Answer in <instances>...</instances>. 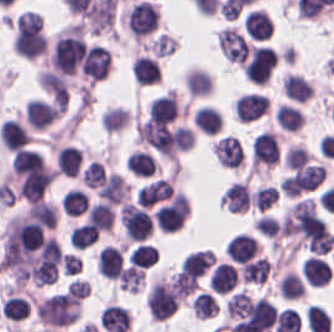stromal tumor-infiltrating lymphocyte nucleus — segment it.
<instances>
[{"instance_id":"stromal-tumor-infiltrating-lymphocyte-nucleus-1","label":"stromal tumor-infiltrating lymphocyte nucleus","mask_w":334,"mask_h":332,"mask_svg":"<svg viewBox=\"0 0 334 332\" xmlns=\"http://www.w3.org/2000/svg\"><path fill=\"white\" fill-rule=\"evenodd\" d=\"M158 21L157 6L146 0L136 1L125 17L129 32L135 36H144L155 28Z\"/></svg>"},{"instance_id":"stromal-tumor-infiltrating-lymphocyte-nucleus-2","label":"stromal tumor-infiltrating lymphocyte nucleus","mask_w":334,"mask_h":332,"mask_svg":"<svg viewBox=\"0 0 334 332\" xmlns=\"http://www.w3.org/2000/svg\"><path fill=\"white\" fill-rule=\"evenodd\" d=\"M148 307L152 316L161 321L177 310V295L166 280L156 279L152 284Z\"/></svg>"},{"instance_id":"stromal-tumor-infiltrating-lymphocyte-nucleus-3","label":"stromal tumor-infiltrating lymphocyte nucleus","mask_w":334,"mask_h":332,"mask_svg":"<svg viewBox=\"0 0 334 332\" xmlns=\"http://www.w3.org/2000/svg\"><path fill=\"white\" fill-rule=\"evenodd\" d=\"M110 51L101 44H88L81 55L82 75L93 80L103 79L109 72Z\"/></svg>"},{"instance_id":"stromal-tumor-infiltrating-lymphocyte-nucleus-4","label":"stromal tumor-infiltrating lymphocyte nucleus","mask_w":334,"mask_h":332,"mask_svg":"<svg viewBox=\"0 0 334 332\" xmlns=\"http://www.w3.org/2000/svg\"><path fill=\"white\" fill-rule=\"evenodd\" d=\"M219 50L227 60L245 63L249 53V42L232 26L221 28L217 36Z\"/></svg>"},{"instance_id":"stromal-tumor-infiltrating-lymphocyte-nucleus-5","label":"stromal tumor-infiltrating lymphocyte nucleus","mask_w":334,"mask_h":332,"mask_svg":"<svg viewBox=\"0 0 334 332\" xmlns=\"http://www.w3.org/2000/svg\"><path fill=\"white\" fill-rule=\"evenodd\" d=\"M212 148L223 167H239L243 163L242 143L237 136L224 134L213 142Z\"/></svg>"},{"instance_id":"stromal-tumor-infiltrating-lymphocyte-nucleus-6","label":"stromal tumor-infiltrating lymphocyte nucleus","mask_w":334,"mask_h":332,"mask_svg":"<svg viewBox=\"0 0 334 332\" xmlns=\"http://www.w3.org/2000/svg\"><path fill=\"white\" fill-rule=\"evenodd\" d=\"M57 111L51 103L31 97L25 103L24 117L31 127L42 130L53 121Z\"/></svg>"},{"instance_id":"stromal-tumor-infiltrating-lymphocyte-nucleus-7","label":"stromal tumor-infiltrating lymphocyte nucleus","mask_w":334,"mask_h":332,"mask_svg":"<svg viewBox=\"0 0 334 332\" xmlns=\"http://www.w3.org/2000/svg\"><path fill=\"white\" fill-rule=\"evenodd\" d=\"M268 105L264 95L255 92L241 94L234 102V116L236 119L254 120L266 111Z\"/></svg>"},{"instance_id":"stromal-tumor-infiltrating-lymphocyte-nucleus-8","label":"stromal tumor-infiltrating lymphocyte nucleus","mask_w":334,"mask_h":332,"mask_svg":"<svg viewBox=\"0 0 334 332\" xmlns=\"http://www.w3.org/2000/svg\"><path fill=\"white\" fill-rule=\"evenodd\" d=\"M123 265V250L119 245L104 244L96 255L99 274L117 278Z\"/></svg>"},{"instance_id":"stromal-tumor-infiltrating-lymphocyte-nucleus-9","label":"stromal tumor-infiltrating lymphocyte nucleus","mask_w":334,"mask_h":332,"mask_svg":"<svg viewBox=\"0 0 334 332\" xmlns=\"http://www.w3.org/2000/svg\"><path fill=\"white\" fill-rule=\"evenodd\" d=\"M237 278L238 273L230 261H217L210 272L208 286L213 292L227 293Z\"/></svg>"},{"instance_id":"stromal-tumor-infiltrating-lymphocyte-nucleus-10","label":"stromal tumor-infiltrating lymphocyte nucleus","mask_w":334,"mask_h":332,"mask_svg":"<svg viewBox=\"0 0 334 332\" xmlns=\"http://www.w3.org/2000/svg\"><path fill=\"white\" fill-rule=\"evenodd\" d=\"M250 203L248 183L234 180L222 193L221 204L236 212H244Z\"/></svg>"},{"instance_id":"stromal-tumor-infiltrating-lymphocyte-nucleus-11","label":"stromal tumor-infiltrating lymphocyte nucleus","mask_w":334,"mask_h":332,"mask_svg":"<svg viewBox=\"0 0 334 332\" xmlns=\"http://www.w3.org/2000/svg\"><path fill=\"white\" fill-rule=\"evenodd\" d=\"M31 137L27 129L13 118H6L0 124L1 143L9 150L15 151L26 145Z\"/></svg>"},{"instance_id":"stromal-tumor-infiltrating-lymphocyte-nucleus-12","label":"stromal tumor-infiltrating lymphocyte nucleus","mask_w":334,"mask_h":332,"mask_svg":"<svg viewBox=\"0 0 334 332\" xmlns=\"http://www.w3.org/2000/svg\"><path fill=\"white\" fill-rule=\"evenodd\" d=\"M259 247L254 235L245 233L234 234L226 245V253L238 261L250 260L258 253Z\"/></svg>"},{"instance_id":"stromal-tumor-infiltrating-lymphocyte-nucleus-13","label":"stromal tumor-infiltrating lymphocyte nucleus","mask_w":334,"mask_h":332,"mask_svg":"<svg viewBox=\"0 0 334 332\" xmlns=\"http://www.w3.org/2000/svg\"><path fill=\"white\" fill-rule=\"evenodd\" d=\"M272 30L273 23L265 10L253 9L244 17V32L252 39L263 41Z\"/></svg>"},{"instance_id":"stromal-tumor-infiltrating-lymphocyte-nucleus-14","label":"stromal tumor-infiltrating lymphocyte nucleus","mask_w":334,"mask_h":332,"mask_svg":"<svg viewBox=\"0 0 334 332\" xmlns=\"http://www.w3.org/2000/svg\"><path fill=\"white\" fill-rule=\"evenodd\" d=\"M305 280L315 285H323L332 276V266L325 259L309 255L300 266Z\"/></svg>"},{"instance_id":"stromal-tumor-infiltrating-lymphocyte-nucleus-15","label":"stromal tumor-infiltrating lymphocyte nucleus","mask_w":334,"mask_h":332,"mask_svg":"<svg viewBox=\"0 0 334 332\" xmlns=\"http://www.w3.org/2000/svg\"><path fill=\"white\" fill-rule=\"evenodd\" d=\"M83 150L74 145L60 147L55 154V169L62 174L74 176L80 170Z\"/></svg>"},{"instance_id":"stromal-tumor-infiltrating-lymphocyte-nucleus-16","label":"stromal tumor-infiltrating lymphocyte nucleus","mask_w":334,"mask_h":332,"mask_svg":"<svg viewBox=\"0 0 334 332\" xmlns=\"http://www.w3.org/2000/svg\"><path fill=\"white\" fill-rule=\"evenodd\" d=\"M86 219L94 229L109 231L114 220L113 206L99 199L87 209Z\"/></svg>"},{"instance_id":"stromal-tumor-infiltrating-lymphocyte-nucleus-17","label":"stromal tumor-infiltrating lymphocyte nucleus","mask_w":334,"mask_h":332,"mask_svg":"<svg viewBox=\"0 0 334 332\" xmlns=\"http://www.w3.org/2000/svg\"><path fill=\"white\" fill-rule=\"evenodd\" d=\"M133 75L141 84L154 82L160 76V66L155 57L136 54L131 66Z\"/></svg>"},{"instance_id":"stromal-tumor-infiltrating-lymphocyte-nucleus-18","label":"stromal tumor-infiltrating lymphocyte nucleus","mask_w":334,"mask_h":332,"mask_svg":"<svg viewBox=\"0 0 334 332\" xmlns=\"http://www.w3.org/2000/svg\"><path fill=\"white\" fill-rule=\"evenodd\" d=\"M193 121L205 133L216 134L223 126V115L211 104H203L196 108Z\"/></svg>"},{"instance_id":"stromal-tumor-infiltrating-lymphocyte-nucleus-19","label":"stromal tumor-infiltrating lymphocyte nucleus","mask_w":334,"mask_h":332,"mask_svg":"<svg viewBox=\"0 0 334 332\" xmlns=\"http://www.w3.org/2000/svg\"><path fill=\"white\" fill-rule=\"evenodd\" d=\"M284 94L298 100L309 99L314 91L313 85L301 73L289 72L283 77Z\"/></svg>"},{"instance_id":"stromal-tumor-infiltrating-lymphocyte-nucleus-20","label":"stromal tumor-infiltrating lymphocyte nucleus","mask_w":334,"mask_h":332,"mask_svg":"<svg viewBox=\"0 0 334 332\" xmlns=\"http://www.w3.org/2000/svg\"><path fill=\"white\" fill-rule=\"evenodd\" d=\"M216 257L212 250L198 249L192 250L181 261L180 267L182 270L200 275L203 273L214 261Z\"/></svg>"},{"instance_id":"stromal-tumor-infiltrating-lymphocyte-nucleus-21","label":"stromal tumor-infiltrating lymphocyte nucleus","mask_w":334,"mask_h":332,"mask_svg":"<svg viewBox=\"0 0 334 332\" xmlns=\"http://www.w3.org/2000/svg\"><path fill=\"white\" fill-rule=\"evenodd\" d=\"M185 86L189 95H208L212 91V77L203 69L192 67L185 74Z\"/></svg>"},{"instance_id":"stromal-tumor-infiltrating-lymphocyte-nucleus-22","label":"stromal tumor-infiltrating lymphocyte nucleus","mask_w":334,"mask_h":332,"mask_svg":"<svg viewBox=\"0 0 334 332\" xmlns=\"http://www.w3.org/2000/svg\"><path fill=\"white\" fill-rule=\"evenodd\" d=\"M60 205L62 212L78 215L85 212L89 205V197L78 187H71L63 192Z\"/></svg>"},{"instance_id":"stromal-tumor-infiltrating-lymphocyte-nucleus-23","label":"stromal tumor-infiltrating lymphocyte nucleus","mask_w":334,"mask_h":332,"mask_svg":"<svg viewBox=\"0 0 334 332\" xmlns=\"http://www.w3.org/2000/svg\"><path fill=\"white\" fill-rule=\"evenodd\" d=\"M125 167L133 173L150 176L155 169V157L147 150L135 149L129 152Z\"/></svg>"},{"instance_id":"stromal-tumor-infiltrating-lymphocyte-nucleus-24","label":"stromal tumor-infiltrating lymphocyte nucleus","mask_w":334,"mask_h":332,"mask_svg":"<svg viewBox=\"0 0 334 332\" xmlns=\"http://www.w3.org/2000/svg\"><path fill=\"white\" fill-rule=\"evenodd\" d=\"M129 113L125 106H105L100 113L99 122L104 131H115L127 124Z\"/></svg>"},{"instance_id":"stromal-tumor-infiltrating-lymphocyte-nucleus-25","label":"stromal tumor-infiltrating lymphocyte nucleus","mask_w":334,"mask_h":332,"mask_svg":"<svg viewBox=\"0 0 334 332\" xmlns=\"http://www.w3.org/2000/svg\"><path fill=\"white\" fill-rule=\"evenodd\" d=\"M29 303L25 297L8 292L0 304V311L12 320H21L29 313Z\"/></svg>"},{"instance_id":"stromal-tumor-infiltrating-lymphocyte-nucleus-26","label":"stromal tumor-infiltrating lymphocyte nucleus","mask_w":334,"mask_h":332,"mask_svg":"<svg viewBox=\"0 0 334 332\" xmlns=\"http://www.w3.org/2000/svg\"><path fill=\"white\" fill-rule=\"evenodd\" d=\"M275 118L285 129H299L304 121V113L296 106L280 103L276 107Z\"/></svg>"},{"instance_id":"stromal-tumor-infiltrating-lymphocyte-nucleus-27","label":"stromal tumor-infiltrating lymphocyte nucleus","mask_w":334,"mask_h":332,"mask_svg":"<svg viewBox=\"0 0 334 332\" xmlns=\"http://www.w3.org/2000/svg\"><path fill=\"white\" fill-rule=\"evenodd\" d=\"M193 316L206 318L218 311V302L214 295L207 290H200L190 302Z\"/></svg>"},{"instance_id":"stromal-tumor-infiltrating-lymphocyte-nucleus-28","label":"stromal tumor-infiltrating lymphocyte nucleus","mask_w":334,"mask_h":332,"mask_svg":"<svg viewBox=\"0 0 334 332\" xmlns=\"http://www.w3.org/2000/svg\"><path fill=\"white\" fill-rule=\"evenodd\" d=\"M277 288L283 296L290 300L302 296L305 292L300 274L289 269L284 272Z\"/></svg>"},{"instance_id":"stromal-tumor-infiltrating-lymphocyte-nucleus-29","label":"stromal tumor-infiltrating lymphocyte nucleus","mask_w":334,"mask_h":332,"mask_svg":"<svg viewBox=\"0 0 334 332\" xmlns=\"http://www.w3.org/2000/svg\"><path fill=\"white\" fill-rule=\"evenodd\" d=\"M144 278V268L129 263L119 272V289L136 292L137 290H139Z\"/></svg>"},{"instance_id":"stromal-tumor-infiltrating-lymphocyte-nucleus-30","label":"stromal tumor-infiltrating lymphocyte nucleus","mask_w":334,"mask_h":332,"mask_svg":"<svg viewBox=\"0 0 334 332\" xmlns=\"http://www.w3.org/2000/svg\"><path fill=\"white\" fill-rule=\"evenodd\" d=\"M170 284L177 295L187 296L198 284V276L190 271L178 270L169 279Z\"/></svg>"},{"instance_id":"stromal-tumor-infiltrating-lymphocyte-nucleus-31","label":"stromal tumor-infiltrating lymphocyte nucleus","mask_w":334,"mask_h":332,"mask_svg":"<svg viewBox=\"0 0 334 332\" xmlns=\"http://www.w3.org/2000/svg\"><path fill=\"white\" fill-rule=\"evenodd\" d=\"M249 310V297L245 289H238L228 297L226 304L227 316H243Z\"/></svg>"},{"instance_id":"stromal-tumor-infiltrating-lymphocyte-nucleus-32","label":"stromal tumor-infiltrating lymphocyte nucleus","mask_w":334,"mask_h":332,"mask_svg":"<svg viewBox=\"0 0 334 332\" xmlns=\"http://www.w3.org/2000/svg\"><path fill=\"white\" fill-rule=\"evenodd\" d=\"M129 257L134 265L147 267L157 259L156 248L151 244L139 243L129 253Z\"/></svg>"},{"instance_id":"stromal-tumor-infiltrating-lymphocyte-nucleus-33","label":"stromal tumor-infiltrating lymphocyte nucleus","mask_w":334,"mask_h":332,"mask_svg":"<svg viewBox=\"0 0 334 332\" xmlns=\"http://www.w3.org/2000/svg\"><path fill=\"white\" fill-rule=\"evenodd\" d=\"M252 204L255 209H265L273 204L277 199L275 188L269 185L258 186L251 193Z\"/></svg>"},{"instance_id":"stromal-tumor-infiltrating-lymphocyte-nucleus-34","label":"stromal tumor-infiltrating lymphocyte nucleus","mask_w":334,"mask_h":332,"mask_svg":"<svg viewBox=\"0 0 334 332\" xmlns=\"http://www.w3.org/2000/svg\"><path fill=\"white\" fill-rule=\"evenodd\" d=\"M104 167L100 160H92L83 169L82 182L86 186L99 187Z\"/></svg>"},{"instance_id":"stromal-tumor-infiltrating-lymphocyte-nucleus-35","label":"stromal tumor-infiltrating lymphocyte nucleus","mask_w":334,"mask_h":332,"mask_svg":"<svg viewBox=\"0 0 334 332\" xmlns=\"http://www.w3.org/2000/svg\"><path fill=\"white\" fill-rule=\"evenodd\" d=\"M285 160L288 166L296 168L308 161L311 157L308 151L301 144H294L285 150Z\"/></svg>"},{"instance_id":"stromal-tumor-infiltrating-lymphocyte-nucleus-36","label":"stromal tumor-infiltrating lymphocyte nucleus","mask_w":334,"mask_h":332,"mask_svg":"<svg viewBox=\"0 0 334 332\" xmlns=\"http://www.w3.org/2000/svg\"><path fill=\"white\" fill-rule=\"evenodd\" d=\"M255 228L258 233L276 237L278 235V221L274 216L267 214H260L256 223Z\"/></svg>"},{"instance_id":"stromal-tumor-infiltrating-lymphocyte-nucleus-37","label":"stromal tumor-infiltrating lymphocyte nucleus","mask_w":334,"mask_h":332,"mask_svg":"<svg viewBox=\"0 0 334 332\" xmlns=\"http://www.w3.org/2000/svg\"><path fill=\"white\" fill-rule=\"evenodd\" d=\"M71 296L83 299L90 292V283L80 278H73L68 281Z\"/></svg>"},{"instance_id":"stromal-tumor-infiltrating-lymphocyte-nucleus-38","label":"stromal tumor-infiltrating lymphocyte nucleus","mask_w":334,"mask_h":332,"mask_svg":"<svg viewBox=\"0 0 334 332\" xmlns=\"http://www.w3.org/2000/svg\"><path fill=\"white\" fill-rule=\"evenodd\" d=\"M61 262L67 275L78 272L80 260L75 253L65 252Z\"/></svg>"}]
</instances>
